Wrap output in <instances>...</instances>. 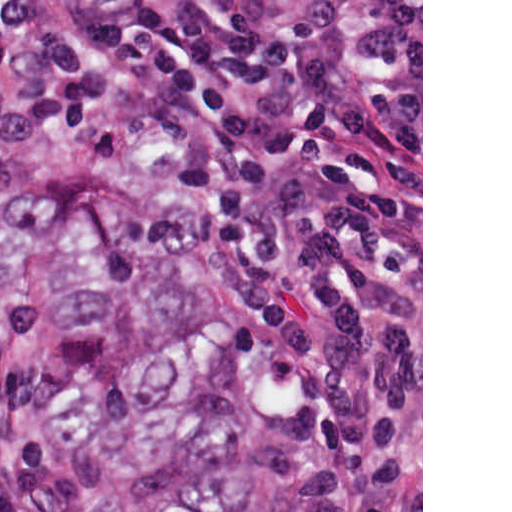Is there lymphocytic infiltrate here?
Wrapping results in <instances>:
<instances>
[{
    "label": "lymphocytic infiltrate",
    "mask_w": 512,
    "mask_h": 512,
    "mask_svg": "<svg viewBox=\"0 0 512 512\" xmlns=\"http://www.w3.org/2000/svg\"><path fill=\"white\" fill-rule=\"evenodd\" d=\"M0 217L162 168L224 210L307 384L294 512H421V0H0ZM0 512H75L0 421Z\"/></svg>",
    "instance_id": "obj_1"
}]
</instances>
